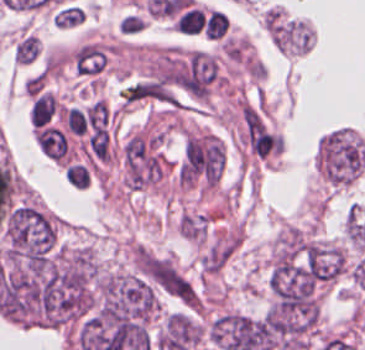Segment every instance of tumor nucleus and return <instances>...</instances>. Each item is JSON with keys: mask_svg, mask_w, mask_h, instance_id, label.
Segmentation results:
<instances>
[{"mask_svg": "<svg viewBox=\"0 0 365 350\" xmlns=\"http://www.w3.org/2000/svg\"><path fill=\"white\" fill-rule=\"evenodd\" d=\"M55 240L56 231L51 218L25 203L11 208L5 225V259L10 263L48 257Z\"/></svg>", "mask_w": 365, "mask_h": 350, "instance_id": "2f306a5c", "label": "tumor nucleus"}, {"mask_svg": "<svg viewBox=\"0 0 365 350\" xmlns=\"http://www.w3.org/2000/svg\"><path fill=\"white\" fill-rule=\"evenodd\" d=\"M319 168L323 175L337 184L353 180L365 163V148L350 128H336L318 142Z\"/></svg>", "mask_w": 365, "mask_h": 350, "instance_id": "8643909e", "label": "tumor nucleus"}, {"mask_svg": "<svg viewBox=\"0 0 365 350\" xmlns=\"http://www.w3.org/2000/svg\"><path fill=\"white\" fill-rule=\"evenodd\" d=\"M39 49L37 36L25 31L14 44L13 57L16 63L29 64L37 58Z\"/></svg>", "mask_w": 365, "mask_h": 350, "instance_id": "5ab6c2c4", "label": "tumor nucleus"}, {"mask_svg": "<svg viewBox=\"0 0 365 350\" xmlns=\"http://www.w3.org/2000/svg\"><path fill=\"white\" fill-rule=\"evenodd\" d=\"M83 18V8L76 4H68L55 11L56 23L62 27L79 25L82 23Z\"/></svg>", "mask_w": 365, "mask_h": 350, "instance_id": "2cbd58db", "label": "tumor nucleus"}]
</instances>
